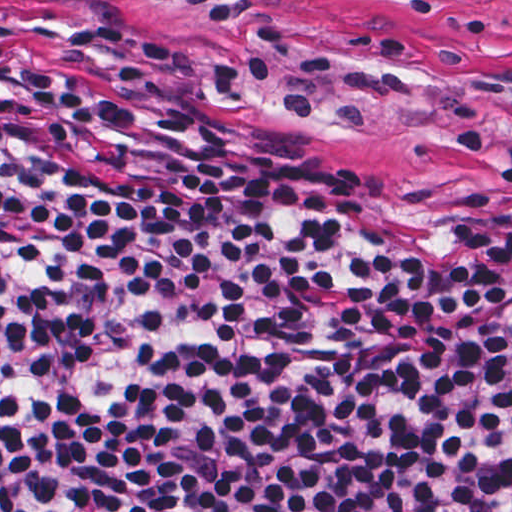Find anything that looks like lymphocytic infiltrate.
<instances>
[{
  "mask_svg": "<svg viewBox=\"0 0 512 512\" xmlns=\"http://www.w3.org/2000/svg\"><path fill=\"white\" fill-rule=\"evenodd\" d=\"M0 512H512V197L404 212L0 22Z\"/></svg>",
  "mask_w": 512,
  "mask_h": 512,
  "instance_id": "f902f5d3",
  "label": "lymphocytic infiltrate"
}]
</instances>
